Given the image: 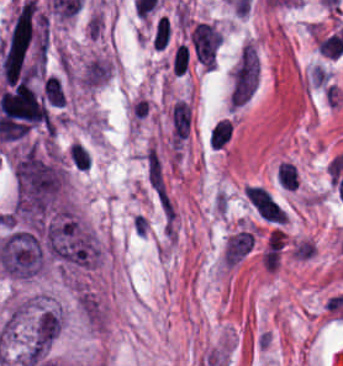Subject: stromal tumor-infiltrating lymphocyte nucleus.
<instances>
[{
    "instance_id": "stromal-tumor-infiltrating-lymphocyte-nucleus-5",
    "label": "stromal tumor-infiltrating lymphocyte nucleus",
    "mask_w": 343,
    "mask_h": 366,
    "mask_svg": "<svg viewBox=\"0 0 343 366\" xmlns=\"http://www.w3.org/2000/svg\"><path fill=\"white\" fill-rule=\"evenodd\" d=\"M169 33L167 17L160 16L153 31L152 45L154 48L163 49Z\"/></svg>"
},
{
    "instance_id": "stromal-tumor-infiltrating-lymphocyte-nucleus-2",
    "label": "stromal tumor-infiltrating lymphocyte nucleus",
    "mask_w": 343,
    "mask_h": 366,
    "mask_svg": "<svg viewBox=\"0 0 343 366\" xmlns=\"http://www.w3.org/2000/svg\"><path fill=\"white\" fill-rule=\"evenodd\" d=\"M231 135V127L228 119L216 122L210 131L209 142L212 148H221Z\"/></svg>"
},
{
    "instance_id": "stromal-tumor-infiltrating-lymphocyte-nucleus-1",
    "label": "stromal tumor-infiltrating lymphocyte nucleus",
    "mask_w": 343,
    "mask_h": 366,
    "mask_svg": "<svg viewBox=\"0 0 343 366\" xmlns=\"http://www.w3.org/2000/svg\"><path fill=\"white\" fill-rule=\"evenodd\" d=\"M64 157L75 171L83 172L90 166L89 150L74 141L69 145Z\"/></svg>"
},
{
    "instance_id": "stromal-tumor-infiltrating-lymphocyte-nucleus-3",
    "label": "stromal tumor-infiltrating lymphocyte nucleus",
    "mask_w": 343,
    "mask_h": 366,
    "mask_svg": "<svg viewBox=\"0 0 343 366\" xmlns=\"http://www.w3.org/2000/svg\"><path fill=\"white\" fill-rule=\"evenodd\" d=\"M278 182L286 189H295L297 187L296 170L292 162L279 161L275 172Z\"/></svg>"
},
{
    "instance_id": "stromal-tumor-infiltrating-lymphocyte-nucleus-4",
    "label": "stromal tumor-infiltrating lymphocyte nucleus",
    "mask_w": 343,
    "mask_h": 366,
    "mask_svg": "<svg viewBox=\"0 0 343 366\" xmlns=\"http://www.w3.org/2000/svg\"><path fill=\"white\" fill-rule=\"evenodd\" d=\"M189 49L185 44H178L171 59L170 69L179 76L186 71Z\"/></svg>"
}]
</instances>
